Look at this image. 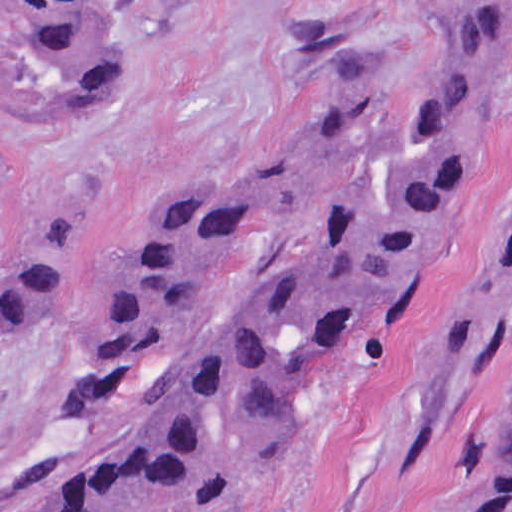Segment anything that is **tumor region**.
<instances>
[{"label": "tumor region", "mask_w": 512, "mask_h": 512, "mask_svg": "<svg viewBox=\"0 0 512 512\" xmlns=\"http://www.w3.org/2000/svg\"><path fill=\"white\" fill-rule=\"evenodd\" d=\"M178 0H58L31 46L44 120L123 96ZM506 0H456L388 77L225 188L109 295L67 479L71 512H180L275 435L329 350L417 280L471 175ZM71 205L24 231L0 171V346L72 278ZM495 265L512 284V180ZM512 512V393L482 462Z\"/></svg>", "instance_id": "obj_1"}]
</instances>
